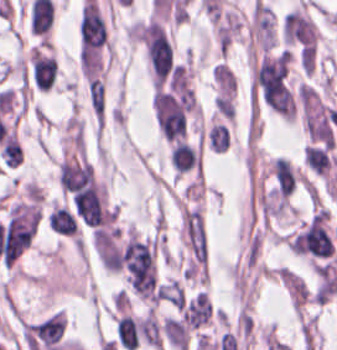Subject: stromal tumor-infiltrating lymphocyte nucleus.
<instances>
[{
    "instance_id": "obj_1",
    "label": "stromal tumor-infiltrating lymphocyte nucleus",
    "mask_w": 337,
    "mask_h": 350,
    "mask_svg": "<svg viewBox=\"0 0 337 350\" xmlns=\"http://www.w3.org/2000/svg\"><path fill=\"white\" fill-rule=\"evenodd\" d=\"M28 58L32 83L36 89H49L55 72V60L53 56L34 47L28 49Z\"/></svg>"
},
{
    "instance_id": "obj_2",
    "label": "stromal tumor-infiltrating lymphocyte nucleus",
    "mask_w": 337,
    "mask_h": 350,
    "mask_svg": "<svg viewBox=\"0 0 337 350\" xmlns=\"http://www.w3.org/2000/svg\"><path fill=\"white\" fill-rule=\"evenodd\" d=\"M306 166L317 176H327L335 159L328 148L320 145L305 144L302 148Z\"/></svg>"
},
{
    "instance_id": "obj_3",
    "label": "stromal tumor-infiltrating lymphocyte nucleus",
    "mask_w": 337,
    "mask_h": 350,
    "mask_svg": "<svg viewBox=\"0 0 337 350\" xmlns=\"http://www.w3.org/2000/svg\"><path fill=\"white\" fill-rule=\"evenodd\" d=\"M170 165L175 175H181L196 164V153L184 140H176L169 150Z\"/></svg>"
},
{
    "instance_id": "obj_4",
    "label": "stromal tumor-infiltrating lymphocyte nucleus",
    "mask_w": 337,
    "mask_h": 350,
    "mask_svg": "<svg viewBox=\"0 0 337 350\" xmlns=\"http://www.w3.org/2000/svg\"><path fill=\"white\" fill-rule=\"evenodd\" d=\"M48 228L53 232L66 236H73L78 224L73 215L65 208L53 206L47 217Z\"/></svg>"
},
{
    "instance_id": "obj_6",
    "label": "stromal tumor-infiltrating lymphocyte nucleus",
    "mask_w": 337,
    "mask_h": 350,
    "mask_svg": "<svg viewBox=\"0 0 337 350\" xmlns=\"http://www.w3.org/2000/svg\"><path fill=\"white\" fill-rule=\"evenodd\" d=\"M207 145L213 153H223L228 149L229 136L220 123H212L207 129Z\"/></svg>"
},
{
    "instance_id": "obj_5",
    "label": "stromal tumor-infiltrating lymphocyte nucleus",
    "mask_w": 337,
    "mask_h": 350,
    "mask_svg": "<svg viewBox=\"0 0 337 350\" xmlns=\"http://www.w3.org/2000/svg\"><path fill=\"white\" fill-rule=\"evenodd\" d=\"M115 333L126 350H133L139 341L136 320L129 314H121L116 320Z\"/></svg>"
}]
</instances>
